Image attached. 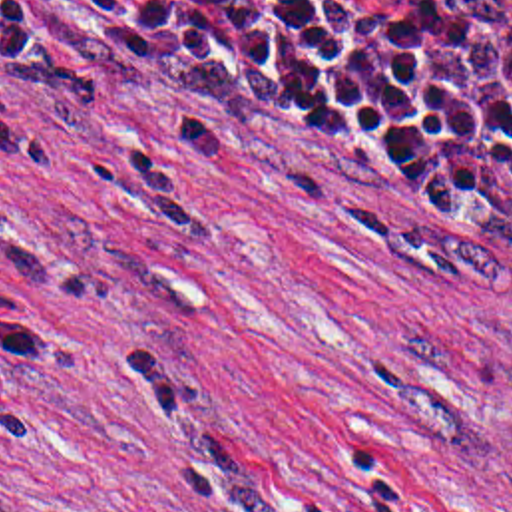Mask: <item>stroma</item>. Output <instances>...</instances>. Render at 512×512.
I'll use <instances>...</instances> for the list:
<instances>
[{
    "label": "stroma",
    "mask_w": 512,
    "mask_h": 512,
    "mask_svg": "<svg viewBox=\"0 0 512 512\" xmlns=\"http://www.w3.org/2000/svg\"><path fill=\"white\" fill-rule=\"evenodd\" d=\"M0 512H512V254L258 122L0 81Z\"/></svg>",
    "instance_id": "1"
}]
</instances>
